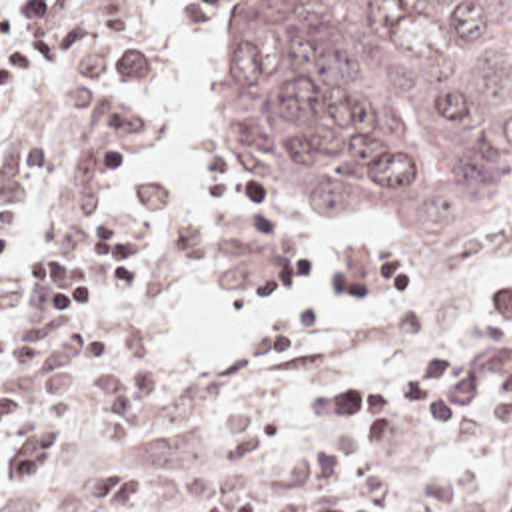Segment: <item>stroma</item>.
<instances>
[{"label":"stroma","instance_id":"1","mask_svg":"<svg viewBox=\"0 0 512 512\" xmlns=\"http://www.w3.org/2000/svg\"><path fill=\"white\" fill-rule=\"evenodd\" d=\"M0 2H72L92 20L94 32L82 46L100 38L128 36L144 46V80L114 96L126 102L154 72V44L142 38L138 2H174L172 14L204 24L208 2H467L475 8H501L512 0H0ZM152 128L138 120L130 154L150 144ZM114 170L100 168L86 150L82 116L60 108L56 66L42 64L22 96L0 110V218L16 222V252L4 268H22L24 256L42 248H80V228L100 216H120L148 230L152 240V280L118 296L96 290L92 304L74 317L118 327L126 347L152 371V409L134 441L104 449L94 421L62 423L66 445L56 461L40 469L36 481L128 461L138 467V485L130 512H200L212 493L254 491L283 493L277 471L301 453V445L281 453L258 471L228 465L220 443V415L226 403L246 401L265 407L263 375L256 355L279 343L299 325L303 313H287L246 355H222L192 363L180 349L176 327L160 312L148 292L178 274L194 256V230L180 216L154 228L156 212L168 192L164 180L140 176L132 208L108 206L106 186ZM236 208L224 226L222 280L234 288H258L271 280H291L309 260L311 196H329L345 214L373 220L391 232V244L367 252H349L339 286L345 298L371 304L385 292L415 282L449 278L425 274L407 254L401 234L377 212L331 194H283L230 184ZM512 246V202L497 214L489 248ZM74 300H58L68 310ZM483 323L439 343L461 345L483 335ZM357 371L353 359L331 345L305 349L293 383L297 401L317 373ZM289 423V421H277ZM313 435L341 469V491L365 511H393L409 489L429 475L457 477L463 501L457 512H512V427L491 429L475 409L461 425L415 423L389 447L353 453L345 445V421L315 417ZM86 499L48 503L14 489L0 493V512H78Z\"/></svg>","mask_w":512,"mask_h":512}]
</instances>
